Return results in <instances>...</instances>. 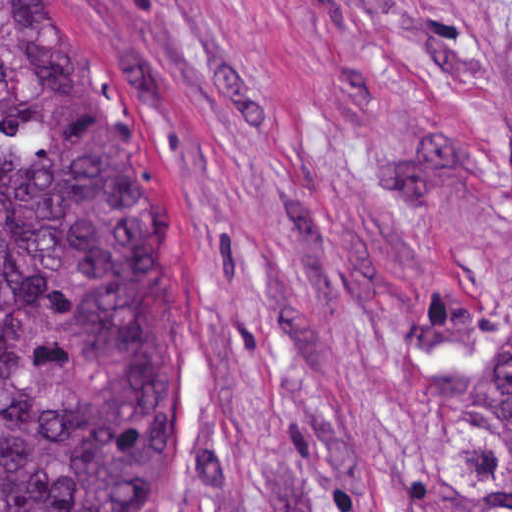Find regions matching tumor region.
Instances as JSON below:
<instances>
[{
	"mask_svg": "<svg viewBox=\"0 0 512 512\" xmlns=\"http://www.w3.org/2000/svg\"><path fill=\"white\" fill-rule=\"evenodd\" d=\"M187 399L168 195L46 0H0V512H148ZM443 512H512V343L434 400Z\"/></svg>",
	"mask_w": 512,
	"mask_h": 512,
	"instance_id": "tumor-region-1",
	"label": "tumor region"
}]
</instances>
